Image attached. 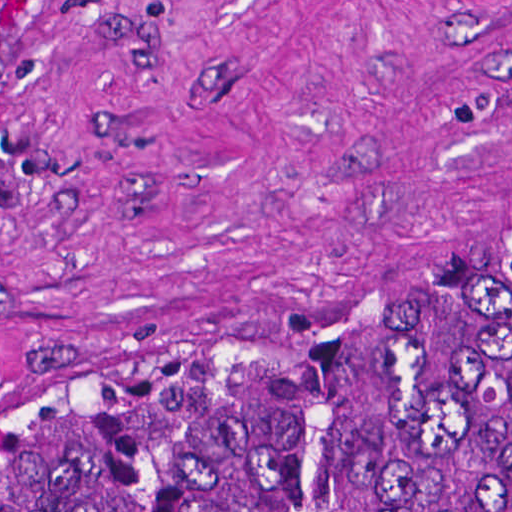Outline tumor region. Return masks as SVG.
Wrapping results in <instances>:
<instances>
[{"mask_svg": "<svg viewBox=\"0 0 512 512\" xmlns=\"http://www.w3.org/2000/svg\"><path fill=\"white\" fill-rule=\"evenodd\" d=\"M0 512H512V272L427 327L279 351L196 396L17 404Z\"/></svg>", "mask_w": 512, "mask_h": 512, "instance_id": "tumor-region-1", "label": "tumor region"}]
</instances>
